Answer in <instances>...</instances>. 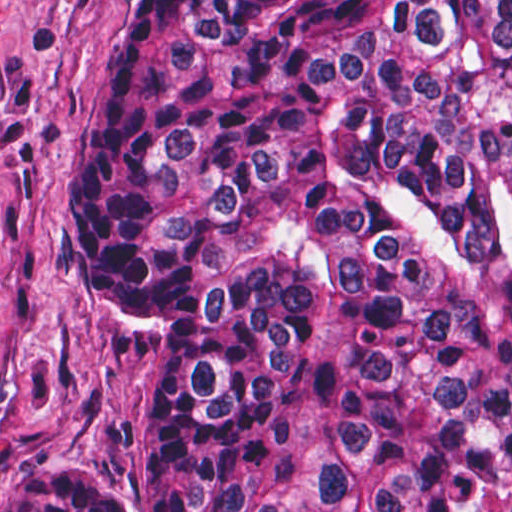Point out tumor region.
Here are the masks:
<instances>
[{
  "instance_id": "tumor-region-1",
  "label": "tumor region",
  "mask_w": 512,
  "mask_h": 512,
  "mask_svg": "<svg viewBox=\"0 0 512 512\" xmlns=\"http://www.w3.org/2000/svg\"><path fill=\"white\" fill-rule=\"evenodd\" d=\"M65 250L151 358L135 512H474L512 465V0H133ZM26 470L1 512H114Z\"/></svg>"
}]
</instances>
